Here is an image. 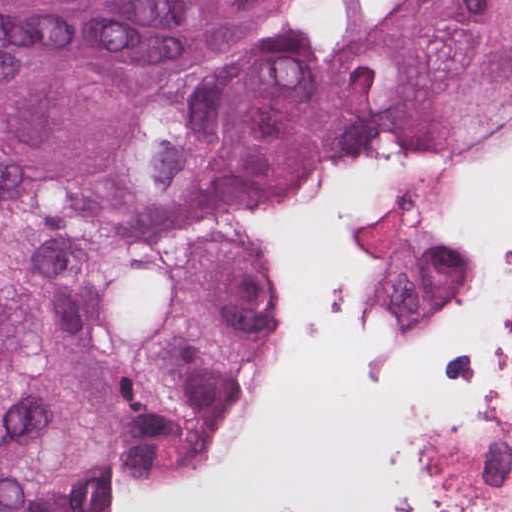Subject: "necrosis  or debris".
Listing matches in <instances>:
<instances>
[{
    "instance_id": "1",
    "label": "necrosis or debris",
    "mask_w": 512,
    "mask_h": 512,
    "mask_svg": "<svg viewBox=\"0 0 512 512\" xmlns=\"http://www.w3.org/2000/svg\"><path fill=\"white\" fill-rule=\"evenodd\" d=\"M253 229L268 301L328 275L366 356L512 358V134L326 148L264 185Z\"/></svg>"
}]
</instances>
